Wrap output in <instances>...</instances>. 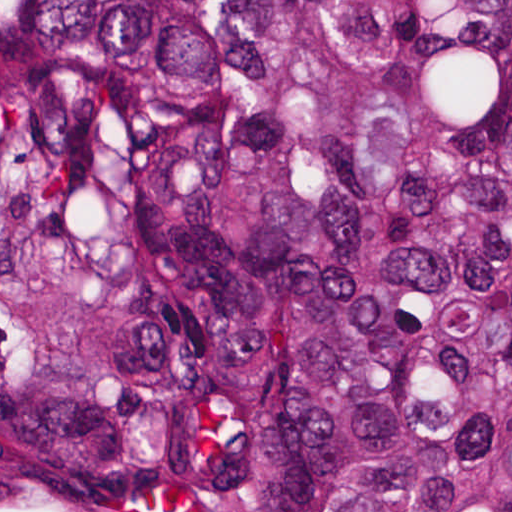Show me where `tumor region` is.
<instances>
[{"mask_svg": "<svg viewBox=\"0 0 512 512\" xmlns=\"http://www.w3.org/2000/svg\"><path fill=\"white\" fill-rule=\"evenodd\" d=\"M0 512H512V0H0Z\"/></svg>", "mask_w": 512, "mask_h": 512, "instance_id": "tumor-region-1", "label": "tumor region"}]
</instances>
